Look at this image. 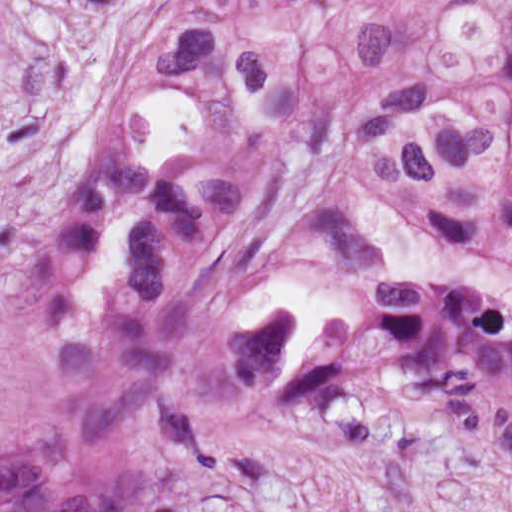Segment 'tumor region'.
<instances>
[{
  "mask_svg": "<svg viewBox=\"0 0 512 512\" xmlns=\"http://www.w3.org/2000/svg\"><path fill=\"white\" fill-rule=\"evenodd\" d=\"M293 404L512 444V0H172L0 292V512H150Z\"/></svg>",
  "mask_w": 512,
  "mask_h": 512,
  "instance_id": "e687c5a6",
  "label": "tumor region"
}]
</instances>
